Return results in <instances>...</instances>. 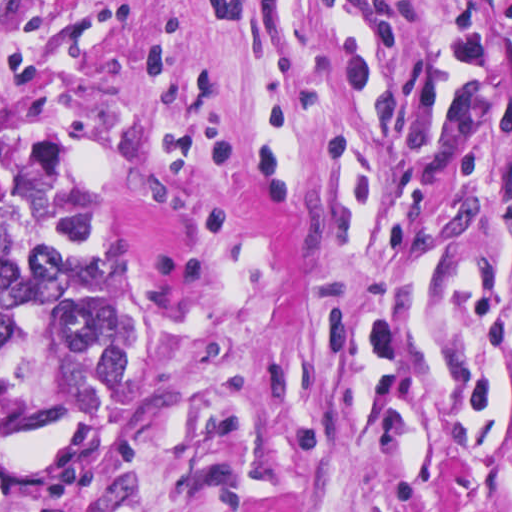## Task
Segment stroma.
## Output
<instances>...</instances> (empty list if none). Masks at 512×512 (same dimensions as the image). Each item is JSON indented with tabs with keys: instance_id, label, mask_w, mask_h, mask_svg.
I'll list each match as a JSON object with an SVG mask.
<instances>
[{
	"instance_id": "35a3bbf8",
	"label": "stroma",
	"mask_w": 512,
	"mask_h": 512,
	"mask_svg": "<svg viewBox=\"0 0 512 512\" xmlns=\"http://www.w3.org/2000/svg\"><path fill=\"white\" fill-rule=\"evenodd\" d=\"M118 266L111 512H512V0H0V195Z\"/></svg>"
}]
</instances>
